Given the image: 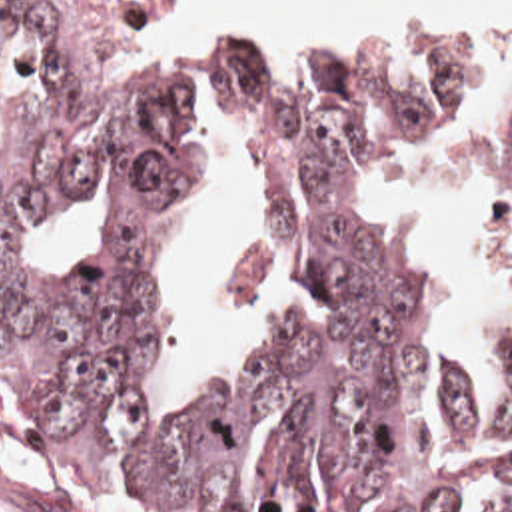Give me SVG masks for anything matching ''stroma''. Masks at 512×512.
Wrapping results in <instances>:
<instances>
[{"label":"stroma","instance_id":"1","mask_svg":"<svg viewBox=\"0 0 512 512\" xmlns=\"http://www.w3.org/2000/svg\"><path fill=\"white\" fill-rule=\"evenodd\" d=\"M101 74H105V72H101ZM107 78H111V76H107ZM111 80L152 82L154 88L160 92L170 116L178 124L168 90L152 74L136 72L129 78H111ZM196 182H198V160L194 156V186H192L188 204L196 190ZM390 262L396 266L394 260H390ZM148 366H150V358H148ZM452 368L464 380V384L472 396V384H470V376L466 374V370L456 364H452ZM510 464H512V456H510L506 468L494 471L480 450V489H478L472 505L466 507L462 512L470 511L472 507L480 505L498 487L502 475L506 473ZM0 512L178 511H168V509L146 505L107 483L83 479L73 469L67 468L39 438L25 436V434H0Z\"/></svg>","mask_w":512,"mask_h":512}]
</instances>
